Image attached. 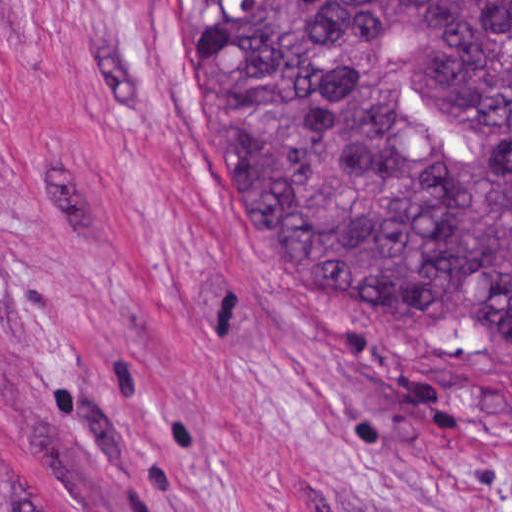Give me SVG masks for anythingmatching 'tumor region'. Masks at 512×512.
Wrapping results in <instances>:
<instances>
[{
    "label": "tumor region",
    "instance_id": "tumor-region-1",
    "mask_svg": "<svg viewBox=\"0 0 512 512\" xmlns=\"http://www.w3.org/2000/svg\"><path fill=\"white\" fill-rule=\"evenodd\" d=\"M190 48L295 280L512 351V0H190ZM0 512H45L1 454Z\"/></svg>",
    "mask_w": 512,
    "mask_h": 512
}]
</instances>
